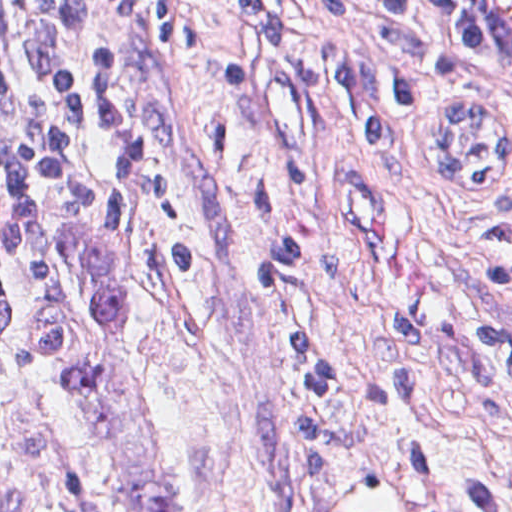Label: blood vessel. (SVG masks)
Wrapping results in <instances>:
<instances>
[{"label": "blood vessel", "instance_id": "blood-vessel-1", "mask_svg": "<svg viewBox=\"0 0 512 512\" xmlns=\"http://www.w3.org/2000/svg\"><path fill=\"white\" fill-rule=\"evenodd\" d=\"M497 66L512 87V0H457Z\"/></svg>", "mask_w": 512, "mask_h": 512}]
</instances>
